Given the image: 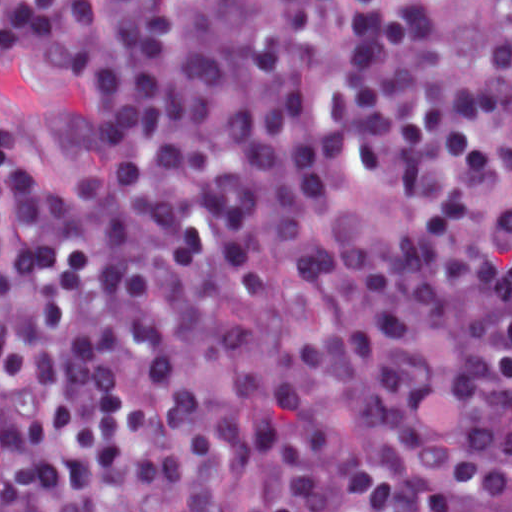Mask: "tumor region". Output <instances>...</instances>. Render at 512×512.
<instances>
[{"label": "tumor region", "instance_id": "1", "mask_svg": "<svg viewBox=\"0 0 512 512\" xmlns=\"http://www.w3.org/2000/svg\"><path fill=\"white\" fill-rule=\"evenodd\" d=\"M472 27L512 61V0H462Z\"/></svg>", "mask_w": 512, "mask_h": 512}]
</instances>
